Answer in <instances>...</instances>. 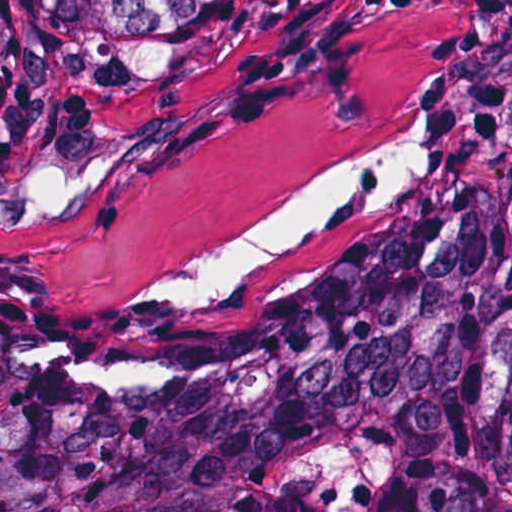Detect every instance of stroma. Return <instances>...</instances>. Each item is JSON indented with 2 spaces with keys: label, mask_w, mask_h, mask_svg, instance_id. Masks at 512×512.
<instances>
[{
  "label": "stroma",
  "mask_w": 512,
  "mask_h": 512,
  "mask_svg": "<svg viewBox=\"0 0 512 512\" xmlns=\"http://www.w3.org/2000/svg\"><path fill=\"white\" fill-rule=\"evenodd\" d=\"M431 90L424 184L379 215L333 217L231 292L512 177V0H256L142 86L49 71L41 113L0 155V206L50 166L120 165L76 215L0 224V294H138L395 141Z\"/></svg>",
  "instance_id": "1"
}]
</instances>
